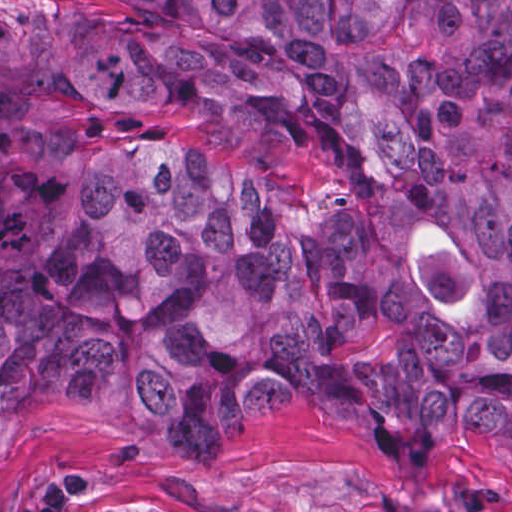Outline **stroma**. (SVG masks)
I'll return each mask as SVG.
<instances>
[{"label":"stroma","instance_id":"35a3bbf8","mask_svg":"<svg viewBox=\"0 0 512 512\" xmlns=\"http://www.w3.org/2000/svg\"><path fill=\"white\" fill-rule=\"evenodd\" d=\"M113 0H0L41 23L96 15ZM512 512V465L463 448L411 466L321 410L255 418L205 445L83 406L47 418L0 477V512Z\"/></svg>","mask_w":512,"mask_h":512}]
</instances>
